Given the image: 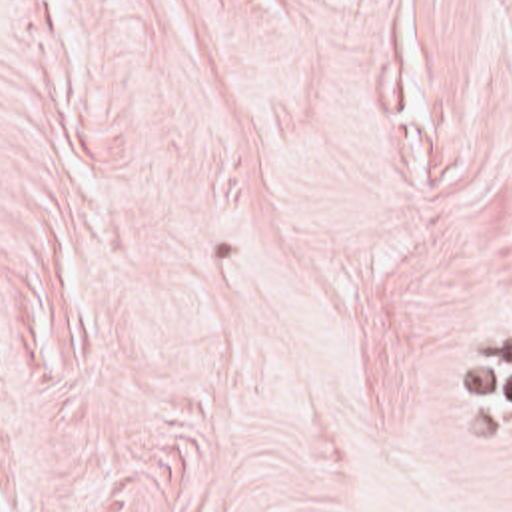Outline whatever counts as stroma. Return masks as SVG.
<instances>
[{"mask_svg":"<svg viewBox=\"0 0 512 512\" xmlns=\"http://www.w3.org/2000/svg\"><path fill=\"white\" fill-rule=\"evenodd\" d=\"M0 512H512V0H0Z\"/></svg>","mask_w":512,"mask_h":512,"instance_id":"stroma-1","label":"stroma"}]
</instances>
